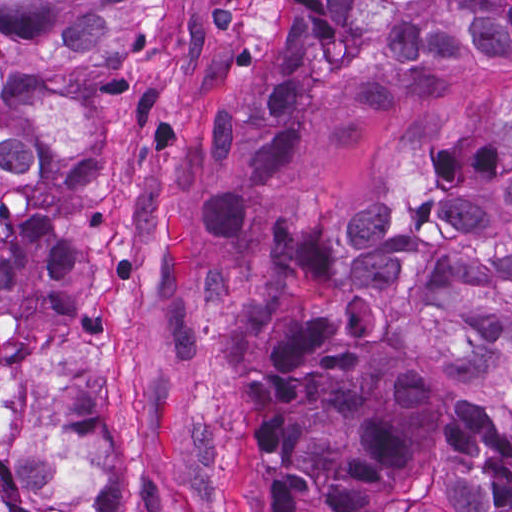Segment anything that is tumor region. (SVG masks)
I'll use <instances>...</instances> for the list:
<instances>
[{
  "label": "tumor region",
  "mask_w": 512,
  "mask_h": 512,
  "mask_svg": "<svg viewBox=\"0 0 512 512\" xmlns=\"http://www.w3.org/2000/svg\"><path fill=\"white\" fill-rule=\"evenodd\" d=\"M147 1H0V512H126L70 345L115 185V65ZM512 62V1H283L210 108L199 228L236 233L306 157ZM267 357L233 394V512H512V93L346 221L267 238Z\"/></svg>",
  "instance_id": "obj_1"
}]
</instances>
